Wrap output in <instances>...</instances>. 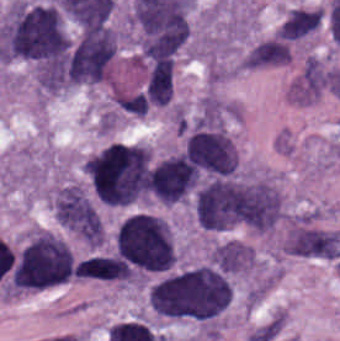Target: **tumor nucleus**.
<instances>
[{"instance_id": "obj_1", "label": "tumor nucleus", "mask_w": 340, "mask_h": 341, "mask_svg": "<svg viewBox=\"0 0 340 341\" xmlns=\"http://www.w3.org/2000/svg\"><path fill=\"white\" fill-rule=\"evenodd\" d=\"M147 296L154 313L162 318L208 321L230 304L231 286L226 273L196 265L155 281Z\"/></svg>"}, {"instance_id": "obj_2", "label": "tumor nucleus", "mask_w": 340, "mask_h": 341, "mask_svg": "<svg viewBox=\"0 0 340 341\" xmlns=\"http://www.w3.org/2000/svg\"><path fill=\"white\" fill-rule=\"evenodd\" d=\"M83 172L99 203L153 198L150 154L142 144L112 141L85 158Z\"/></svg>"}, {"instance_id": "obj_3", "label": "tumor nucleus", "mask_w": 340, "mask_h": 341, "mask_svg": "<svg viewBox=\"0 0 340 341\" xmlns=\"http://www.w3.org/2000/svg\"><path fill=\"white\" fill-rule=\"evenodd\" d=\"M3 60L49 64L67 50L63 18L52 4L15 2L1 29Z\"/></svg>"}, {"instance_id": "obj_4", "label": "tumor nucleus", "mask_w": 340, "mask_h": 341, "mask_svg": "<svg viewBox=\"0 0 340 341\" xmlns=\"http://www.w3.org/2000/svg\"><path fill=\"white\" fill-rule=\"evenodd\" d=\"M113 252L130 274L171 271L174 250L163 221L152 214L134 213L124 218L113 234Z\"/></svg>"}, {"instance_id": "obj_5", "label": "tumor nucleus", "mask_w": 340, "mask_h": 341, "mask_svg": "<svg viewBox=\"0 0 340 341\" xmlns=\"http://www.w3.org/2000/svg\"><path fill=\"white\" fill-rule=\"evenodd\" d=\"M75 267L66 241L50 231H36L13 257L9 288L36 290L67 282Z\"/></svg>"}, {"instance_id": "obj_6", "label": "tumor nucleus", "mask_w": 340, "mask_h": 341, "mask_svg": "<svg viewBox=\"0 0 340 341\" xmlns=\"http://www.w3.org/2000/svg\"><path fill=\"white\" fill-rule=\"evenodd\" d=\"M226 226L268 232L284 215L280 192L266 180L237 179L225 188Z\"/></svg>"}, {"instance_id": "obj_7", "label": "tumor nucleus", "mask_w": 340, "mask_h": 341, "mask_svg": "<svg viewBox=\"0 0 340 341\" xmlns=\"http://www.w3.org/2000/svg\"><path fill=\"white\" fill-rule=\"evenodd\" d=\"M117 51L118 38L110 27L86 29L71 45L65 83L83 86L108 78Z\"/></svg>"}, {"instance_id": "obj_8", "label": "tumor nucleus", "mask_w": 340, "mask_h": 341, "mask_svg": "<svg viewBox=\"0 0 340 341\" xmlns=\"http://www.w3.org/2000/svg\"><path fill=\"white\" fill-rule=\"evenodd\" d=\"M186 153L209 171L231 173L237 166L236 149L224 129H198L188 138Z\"/></svg>"}, {"instance_id": "obj_9", "label": "tumor nucleus", "mask_w": 340, "mask_h": 341, "mask_svg": "<svg viewBox=\"0 0 340 341\" xmlns=\"http://www.w3.org/2000/svg\"><path fill=\"white\" fill-rule=\"evenodd\" d=\"M240 177L203 186L194 194V212L200 227L224 231L232 212Z\"/></svg>"}, {"instance_id": "obj_10", "label": "tumor nucleus", "mask_w": 340, "mask_h": 341, "mask_svg": "<svg viewBox=\"0 0 340 341\" xmlns=\"http://www.w3.org/2000/svg\"><path fill=\"white\" fill-rule=\"evenodd\" d=\"M294 251L302 256L335 259L340 256V234L335 231L297 230Z\"/></svg>"}, {"instance_id": "obj_11", "label": "tumor nucleus", "mask_w": 340, "mask_h": 341, "mask_svg": "<svg viewBox=\"0 0 340 341\" xmlns=\"http://www.w3.org/2000/svg\"><path fill=\"white\" fill-rule=\"evenodd\" d=\"M252 249L238 241H225L213 248L212 264L228 275L250 268Z\"/></svg>"}, {"instance_id": "obj_12", "label": "tumor nucleus", "mask_w": 340, "mask_h": 341, "mask_svg": "<svg viewBox=\"0 0 340 341\" xmlns=\"http://www.w3.org/2000/svg\"><path fill=\"white\" fill-rule=\"evenodd\" d=\"M290 58L288 41L271 37L255 45L242 60L245 66H277L288 62Z\"/></svg>"}, {"instance_id": "obj_13", "label": "tumor nucleus", "mask_w": 340, "mask_h": 341, "mask_svg": "<svg viewBox=\"0 0 340 341\" xmlns=\"http://www.w3.org/2000/svg\"><path fill=\"white\" fill-rule=\"evenodd\" d=\"M146 94L157 107H164L172 96V61L157 60L152 67Z\"/></svg>"}]
</instances>
